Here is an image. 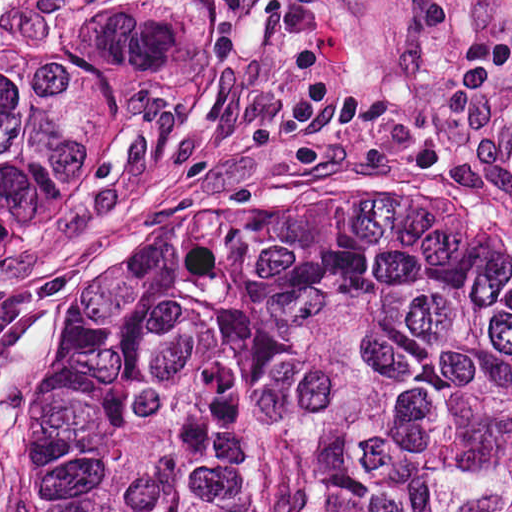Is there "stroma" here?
<instances>
[{
  "instance_id": "35a3bbf8",
  "label": "stroma",
  "mask_w": 512,
  "mask_h": 512,
  "mask_svg": "<svg viewBox=\"0 0 512 512\" xmlns=\"http://www.w3.org/2000/svg\"><path fill=\"white\" fill-rule=\"evenodd\" d=\"M90 2L169 31L96 122L42 235L0 258V512L35 301L95 242L318 197L456 189L512 241V0Z\"/></svg>"
}]
</instances>
